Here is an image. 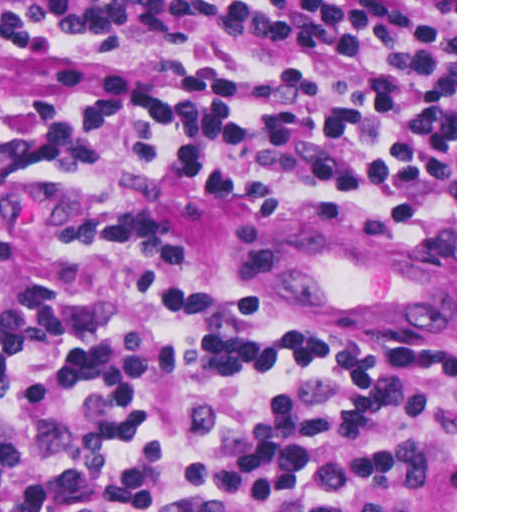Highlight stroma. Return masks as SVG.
Wrapping results in <instances>:
<instances>
[{"label": "stroma", "mask_w": 512, "mask_h": 512, "mask_svg": "<svg viewBox=\"0 0 512 512\" xmlns=\"http://www.w3.org/2000/svg\"><path fill=\"white\" fill-rule=\"evenodd\" d=\"M0 1H455V190L357 215H238L87 169L0 168V278L30 265L75 223H148L241 308H455L457 512V0ZM298 67L288 48L259 33L0 34V68L198 74L281 87Z\"/></svg>", "instance_id": "stroma-1"}]
</instances>
